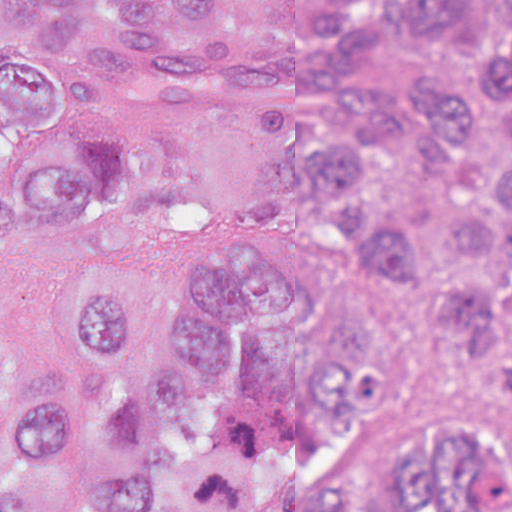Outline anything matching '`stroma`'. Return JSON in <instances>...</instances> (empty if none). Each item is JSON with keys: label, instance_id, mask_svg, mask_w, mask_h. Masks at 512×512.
<instances>
[{"label": "stroma", "instance_id": "stroma-1", "mask_svg": "<svg viewBox=\"0 0 512 512\" xmlns=\"http://www.w3.org/2000/svg\"><path fill=\"white\" fill-rule=\"evenodd\" d=\"M134 15L169 33L229 42L254 54L317 48L365 15L395 32L374 83L403 91L427 71L458 82L484 69L489 42L512 30V0H465L460 14L420 0H233L208 26L184 30L173 3L113 14L87 0L77 35L62 39L83 121L115 130L120 185L101 198L107 252L159 277L180 246L200 237H248L287 246L366 297L383 322L387 380L354 415L342 460L353 480L399 458L422 419L475 411L495 424L512 456V357L488 361L439 316L500 288L506 261L450 255L401 284L370 270L349 221L299 194L288 139L234 116L175 110L125 96L99 77L93 47L104 21ZM60 251L0 248V313L43 403L76 384L59 337ZM49 512H79L68 478Z\"/></svg>", "mask_w": 512, "mask_h": 512}]
</instances>
